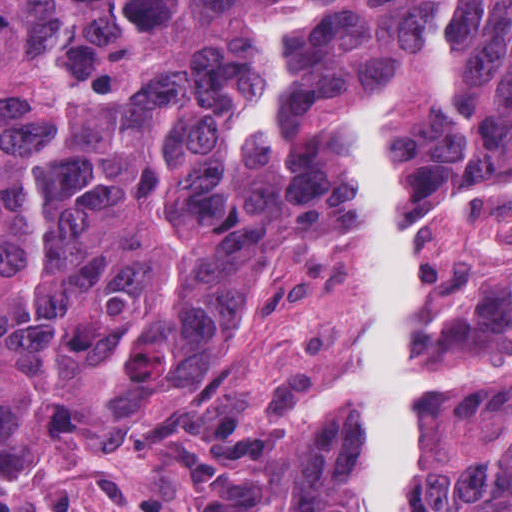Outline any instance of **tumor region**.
I'll return each instance as SVG.
<instances>
[{"mask_svg": "<svg viewBox=\"0 0 512 512\" xmlns=\"http://www.w3.org/2000/svg\"><path fill=\"white\" fill-rule=\"evenodd\" d=\"M400 205L512 169V1H0V428L125 429L276 257L358 232L345 112L392 91ZM425 512H512V350Z\"/></svg>", "mask_w": 512, "mask_h": 512, "instance_id": "1", "label": "tumor region"}]
</instances>
